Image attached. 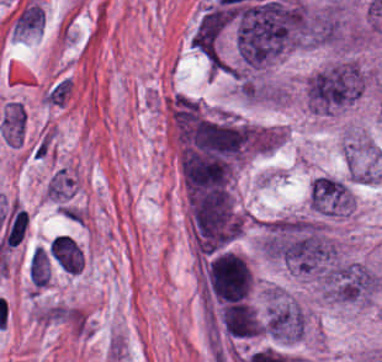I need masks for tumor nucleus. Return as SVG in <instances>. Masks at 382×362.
<instances>
[{
  "label": "tumor nucleus",
  "instance_id": "tumor-nucleus-3",
  "mask_svg": "<svg viewBox=\"0 0 382 362\" xmlns=\"http://www.w3.org/2000/svg\"><path fill=\"white\" fill-rule=\"evenodd\" d=\"M25 110L16 101H9L0 119V129L4 142L21 144Z\"/></svg>",
  "mask_w": 382,
  "mask_h": 362
},
{
  "label": "tumor nucleus",
  "instance_id": "tumor-nucleus-1",
  "mask_svg": "<svg viewBox=\"0 0 382 362\" xmlns=\"http://www.w3.org/2000/svg\"><path fill=\"white\" fill-rule=\"evenodd\" d=\"M364 85L359 64H327L306 78L304 94L308 109L319 115H335L357 103Z\"/></svg>",
  "mask_w": 382,
  "mask_h": 362
},
{
  "label": "tumor nucleus",
  "instance_id": "tumor-nucleus-2",
  "mask_svg": "<svg viewBox=\"0 0 382 362\" xmlns=\"http://www.w3.org/2000/svg\"><path fill=\"white\" fill-rule=\"evenodd\" d=\"M324 295L343 302H363L381 287L378 272L359 261L338 259L322 274Z\"/></svg>",
  "mask_w": 382,
  "mask_h": 362
}]
</instances>
